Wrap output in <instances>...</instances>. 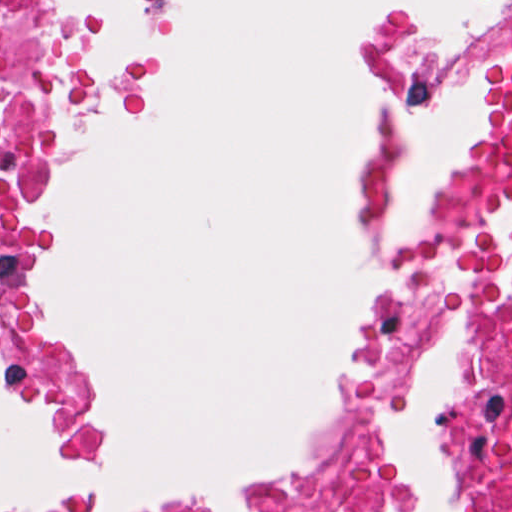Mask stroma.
Segmentation results:
<instances>
[{"mask_svg":"<svg viewBox=\"0 0 512 512\" xmlns=\"http://www.w3.org/2000/svg\"><path fill=\"white\" fill-rule=\"evenodd\" d=\"M75 24V62L64 116L25 206L15 259V302L24 319L42 267L54 246L51 214L68 164L102 123L143 115L165 78L158 61L114 72L102 8L94 0H63ZM376 79L368 125V190L356 205L363 232L375 218L407 131L450 116L423 150L392 212V234L378 259L437 221L464 142L479 128L512 61V0H487V17L471 29L437 21L405 5L386 8L364 24L356 42ZM374 263V264H375ZM81 369L86 403L75 437L39 390L0 364V381L40 411L54 455L73 472L91 475L110 464V433L98 398V372L67 329L35 301L25 321ZM240 470L194 498L223 495L258 477L281 458ZM191 501V500H189ZM171 504H76L54 512H139Z\"/></svg>","mask_w":512,"mask_h":512,"instance_id":"stroma-1","label":"stroma"}]
</instances>
